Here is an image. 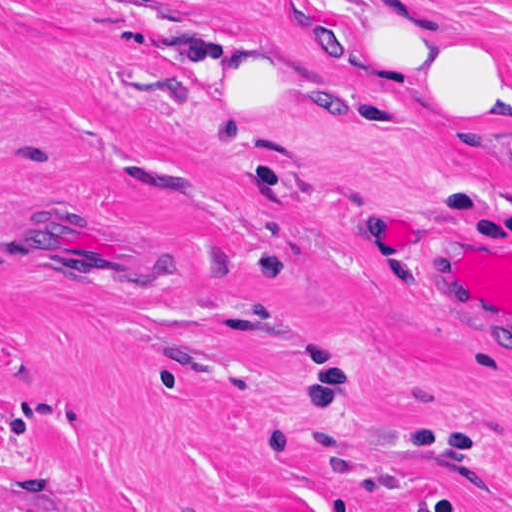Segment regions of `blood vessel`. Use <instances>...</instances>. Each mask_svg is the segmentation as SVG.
I'll use <instances>...</instances> for the list:
<instances>
[{
  "instance_id": "blood-vessel-1",
  "label": "blood vessel",
  "mask_w": 512,
  "mask_h": 512,
  "mask_svg": "<svg viewBox=\"0 0 512 512\" xmlns=\"http://www.w3.org/2000/svg\"><path fill=\"white\" fill-rule=\"evenodd\" d=\"M366 223L395 264H411L407 245L410 222L389 202L366 206ZM439 282L467 306L512 317V250L481 239H454L435 270Z\"/></svg>"
}]
</instances>
